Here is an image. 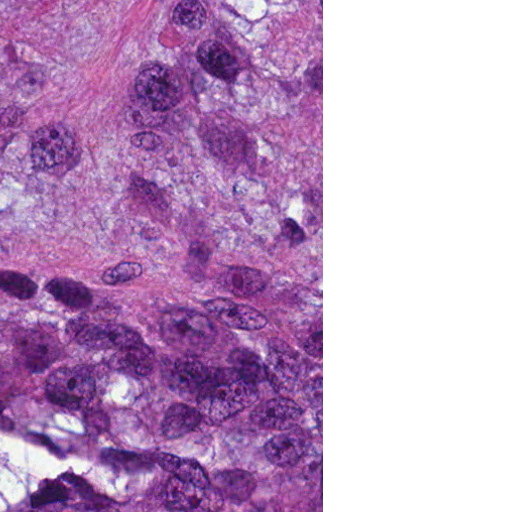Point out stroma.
Masks as SVG:
<instances>
[{"label": "stroma", "instance_id": "stroma-1", "mask_svg": "<svg viewBox=\"0 0 512 512\" xmlns=\"http://www.w3.org/2000/svg\"><path fill=\"white\" fill-rule=\"evenodd\" d=\"M161 512H323V0H161Z\"/></svg>", "mask_w": 512, "mask_h": 512}]
</instances>
